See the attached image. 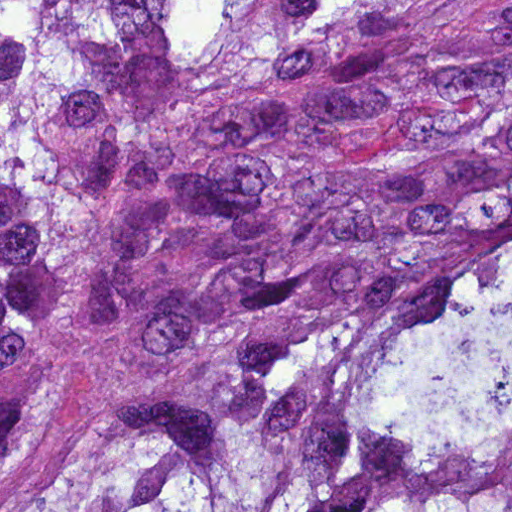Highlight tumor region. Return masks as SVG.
<instances>
[{
	"mask_svg": "<svg viewBox=\"0 0 512 512\" xmlns=\"http://www.w3.org/2000/svg\"><path fill=\"white\" fill-rule=\"evenodd\" d=\"M0 512H512V0H0Z\"/></svg>",
	"mask_w": 512,
	"mask_h": 512,
	"instance_id": "tumor-region-1",
	"label": "tumor region"
}]
</instances>
